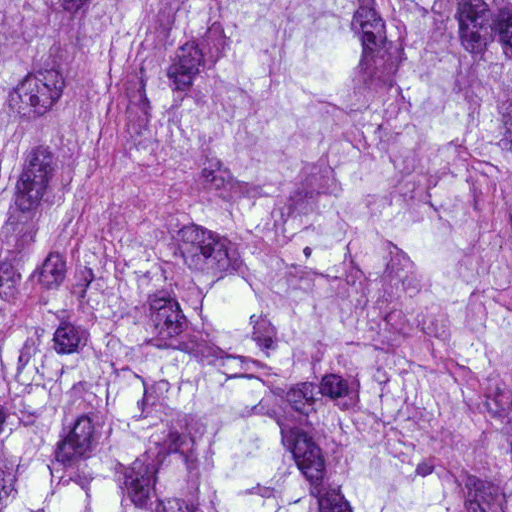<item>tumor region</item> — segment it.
<instances>
[{
    "instance_id": "obj_1",
    "label": "tumor region",
    "mask_w": 512,
    "mask_h": 512,
    "mask_svg": "<svg viewBox=\"0 0 512 512\" xmlns=\"http://www.w3.org/2000/svg\"><path fill=\"white\" fill-rule=\"evenodd\" d=\"M0 512H512V0H0Z\"/></svg>"
}]
</instances>
